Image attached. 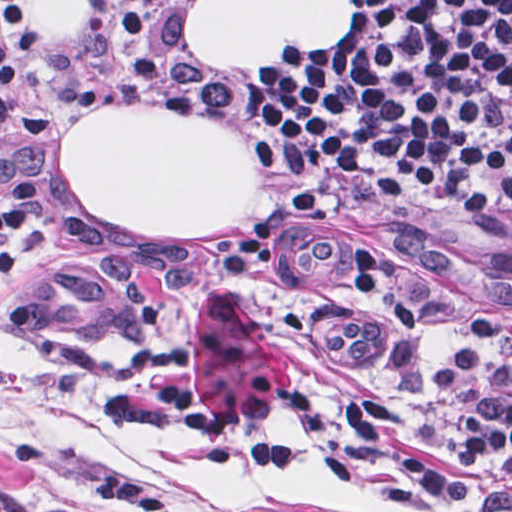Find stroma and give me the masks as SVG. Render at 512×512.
<instances>
[{
	"label": "stroma",
	"instance_id": "1",
	"mask_svg": "<svg viewBox=\"0 0 512 512\" xmlns=\"http://www.w3.org/2000/svg\"><path fill=\"white\" fill-rule=\"evenodd\" d=\"M161 95L120 108H185L241 137L255 210L209 236L108 227L64 174L66 137L113 39L111 0H91L77 39L29 64L26 112L0 143V186L48 188L12 272H0V512H472L424 495L361 455L351 466L253 472L195 466L151 391L169 373L200 405L258 441L342 443L352 401L398 392L458 477L491 482L466 457L455 403L437 389L438 337H407L361 302L350 245L379 246L418 303L512 360V232L448 223L402 201L327 185L277 160L240 97V70H295L357 31L290 53L281 67H213L190 43L196 0H157ZM303 188L319 214L273 237L244 274L224 262L261 216Z\"/></svg>",
	"mask_w": 512,
	"mask_h": 512
}]
</instances>
